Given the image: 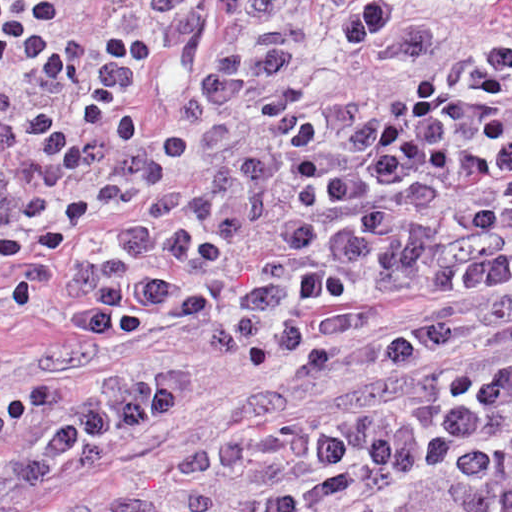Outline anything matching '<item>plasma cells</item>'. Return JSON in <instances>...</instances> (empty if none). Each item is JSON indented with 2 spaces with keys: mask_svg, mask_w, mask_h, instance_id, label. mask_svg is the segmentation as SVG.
Here are the masks:
<instances>
[{
  "mask_svg": "<svg viewBox=\"0 0 512 512\" xmlns=\"http://www.w3.org/2000/svg\"><path fill=\"white\" fill-rule=\"evenodd\" d=\"M334 31L242 115L135 148L0 72V122L54 115L0 149V327L182 325L263 380L228 440L64 512H512V5L401 31L355 0ZM181 411L171 362L0 401V512Z\"/></svg>",
  "mask_w": 512,
  "mask_h": 512,
  "instance_id": "obj_1",
  "label": "plasma cells"
}]
</instances>
